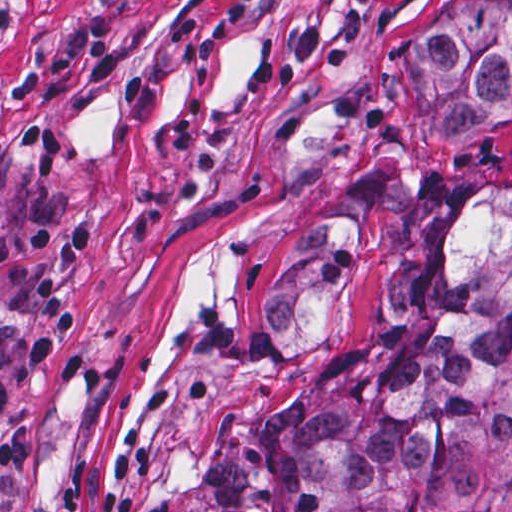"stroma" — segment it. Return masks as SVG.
I'll use <instances>...</instances> for the list:
<instances>
[{"mask_svg": "<svg viewBox=\"0 0 512 512\" xmlns=\"http://www.w3.org/2000/svg\"><path fill=\"white\" fill-rule=\"evenodd\" d=\"M467 0H0V221L100 225L84 268L38 267L80 330L16 377L0 512H193L204 445L312 372L259 358L256 313L310 207L371 203L343 342L383 311L408 196L512 169V101L445 132L412 52ZM0 264V321H32Z\"/></svg>", "mask_w": 512, "mask_h": 512, "instance_id": "1", "label": "stroma"}]
</instances>
